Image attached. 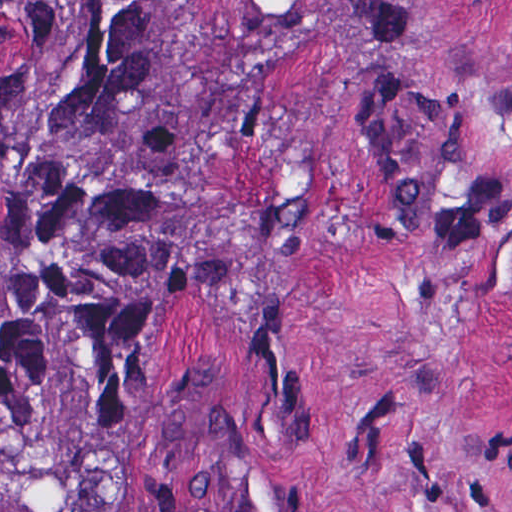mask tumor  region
<instances>
[{
  "label": "tumor region",
  "instance_id": "e687c5a6",
  "mask_svg": "<svg viewBox=\"0 0 512 512\" xmlns=\"http://www.w3.org/2000/svg\"><path fill=\"white\" fill-rule=\"evenodd\" d=\"M193 0H0V512H127L123 373L214 240L178 111Z\"/></svg>",
  "mask_w": 512,
  "mask_h": 512
}]
</instances>
